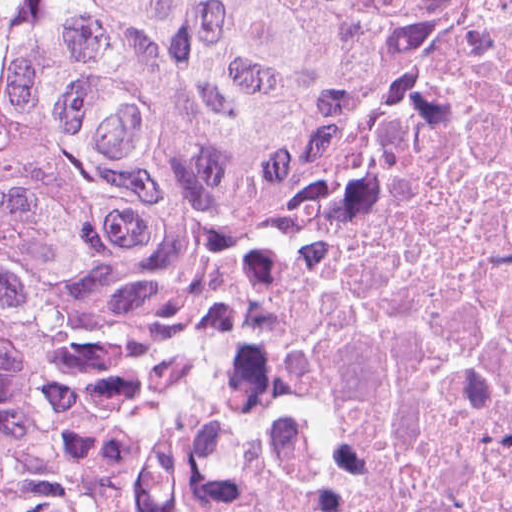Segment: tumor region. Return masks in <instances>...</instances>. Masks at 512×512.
Wrapping results in <instances>:
<instances>
[{
    "label": "tumor region",
    "instance_id": "obj_1",
    "mask_svg": "<svg viewBox=\"0 0 512 512\" xmlns=\"http://www.w3.org/2000/svg\"><path fill=\"white\" fill-rule=\"evenodd\" d=\"M430 0H33L0 71V512H165L427 74Z\"/></svg>",
    "mask_w": 512,
    "mask_h": 512
}]
</instances>
